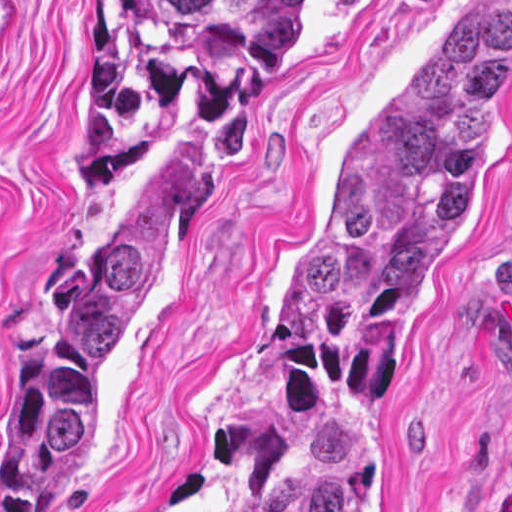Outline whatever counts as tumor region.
Segmentation results:
<instances>
[{"label":"tumor region","instance_id":"obj_1","mask_svg":"<svg viewBox=\"0 0 512 512\" xmlns=\"http://www.w3.org/2000/svg\"><path fill=\"white\" fill-rule=\"evenodd\" d=\"M302 0H100V76L72 189L114 186L193 98L178 144L59 306L34 356V455L0 512H36L98 450L182 270L253 91ZM512 114V25L455 9L386 86L286 264L253 383L205 441L228 512H361L439 290Z\"/></svg>","mask_w":512,"mask_h":512}]
</instances>
